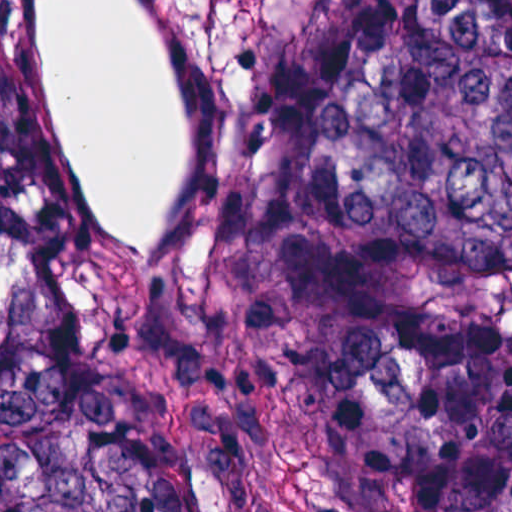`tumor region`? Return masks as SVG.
Returning a JSON list of instances; mask_svg holds the SVG:
<instances>
[{
	"label": "tumor region",
	"mask_w": 512,
	"mask_h": 512,
	"mask_svg": "<svg viewBox=\"0 0 512 512\" xmlns=\"http://www.w3.org/2000/svg\"><path fill=\"white\" fill-rule=\"evenodd\" d=\"M0 512H512V0H0Z\"/></svg>",
	"instance_id": "obj_1"
}]
</instances>
